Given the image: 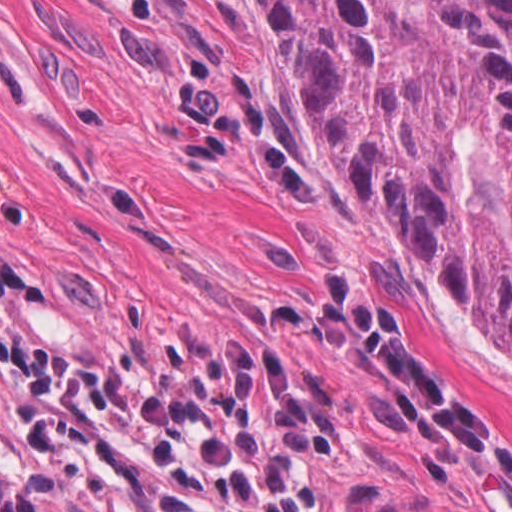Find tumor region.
I'll list each match as a JSON object with an SVG mask.
<instances>
[{"mask_svg": "<svg viewBox=\"0 0 512 512\" xmlns=\"http://www.w3.org/2000/svg\"><path fill=\"white\" fill-rule=\"evenodd\" d=\"M313 142L512 350V0H242ZM0 512H46L0 476Z\"/></svg>", "mask_w": 512, "mask_h": 512, "instance_id": "obj_1", "label": "tumor region"}]
</instances>
